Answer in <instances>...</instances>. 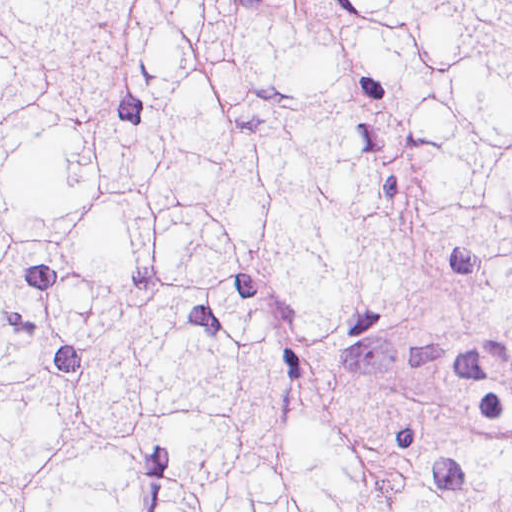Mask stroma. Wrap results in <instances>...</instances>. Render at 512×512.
Instances as JSON below:
<instances>
[{
  "instance_id": "obj_1",
  "label": "stroma",
  "mask_w": 512,
  "mask_h": 512,
  "mask_svg": "<svg viewBox=\"0 0 512 512\" xmlns=\"http://www.w3.org/2000/svg\"><path fill=\"white\" fill-rule=\"evenodd\" d=\"M1 1H512V0H0V512H1Z\"/></svg>"
}]
</instances>
